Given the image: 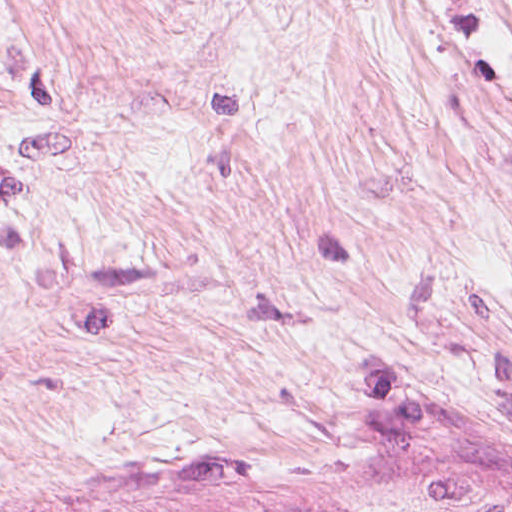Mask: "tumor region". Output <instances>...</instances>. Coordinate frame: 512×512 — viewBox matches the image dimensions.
Returning <instances> with one entry per match:
<instances>
[{
    "label": "tumor region",
    "instance_id": "tumor-region-1",
    "mask_svg": "<svg viewBox=\"0 0 512 512\" xmlns=\"http://www.w3.org/2000/svg\"><path fill=\"white\" fill-rule=\"evenodd\" d=\"M232 512H512V509L404 492L322 505L301 501L276 502Z\"/></svg>",
    "mask_w": 512,
    "mask_h": 512
}]
</instances>
